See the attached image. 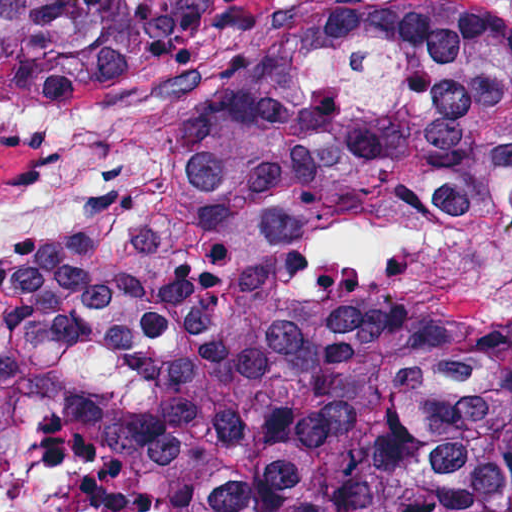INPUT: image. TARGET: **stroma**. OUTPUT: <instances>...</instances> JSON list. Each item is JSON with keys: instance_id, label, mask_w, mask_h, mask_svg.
Here are the masks:
<instances>
[{"instance_id": "1", "label": "stroma", "mask_w": 512, "mask_h": 512, "mask_svg": "<svg viewBox=\"0 0 512 512\" xmlns=\"http://www.w3.org/2000/svg\"><path fill=\"white\" fill-rule=\"evenodd\" d=\"M296 1L220 0L201 39L208 50L178 74L65 103L0 89V103L136 107L170 182L189 108L249 32ZM458 1L512 19V0ZM45 158L0 147V198L39 173ZM165 190L116 239L92 247L135 235ZM52 245L0 244V256ZM291 294L322 346H388L512 319V169H383L333 190L291 230Z\"/></svg>"}]
</instances>
